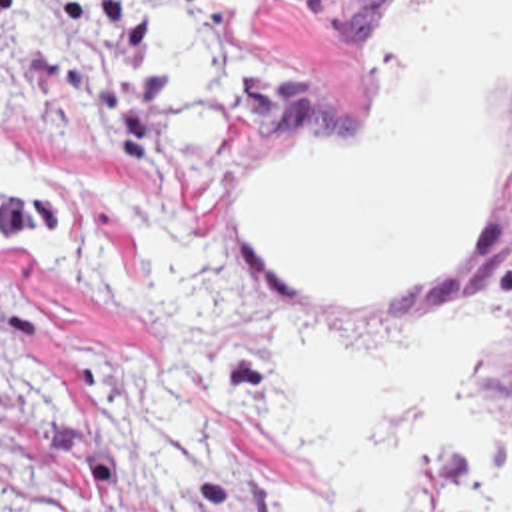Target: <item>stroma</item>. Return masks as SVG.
Listing matches in <instances>:
<instances>
[{
	"instance_id": "stroma-1",
	"label": "stroma",
	"mask_w": 512,
	"mask_h": 512,
	"mask_svg": "<svg viewBox=\"0 0 512 512\" xmlns=\"http://www.w3.org/2000/svg\"><path fill=\"white\" fill-rule=\"evenodd\" d=\"M361 7L254 1L242 41L264 85L206 167L202 223L170 277H130L110 243L0 255V512H337L264 414V357L282 341L385 345L433 297L512 291V169L461 259L403 303H343L250 253L244 143L361 113L385 59ZM481 398L512 430V333L485 347ZM411 512L471 508L463 482L427 464Z\"/></svg>"
}]
</instances>
